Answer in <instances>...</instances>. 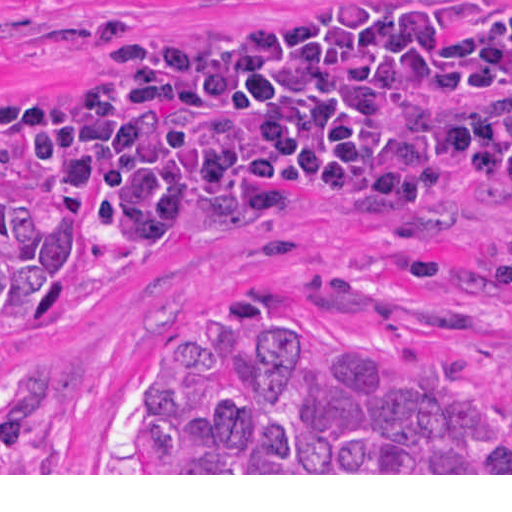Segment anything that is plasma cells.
I'll return each mask as SVG.
<instances>
[{"mask_svg":"<svg viewBox=\"0 0 512 512\" xmlns=\"http://www.w3.org/2000/svg\"><path fill=\"white\" fill-rule=\"evenodd\" d=\"M0 142L140 254L332 194L438 203L512 180V0H301L243 41L103 26L73 90L0 93Z\"/></svg>","mask_w":512,"mask_h":512,"instance_id":"plasma-cells-1","label":"plasma cells"}]
</instances>
